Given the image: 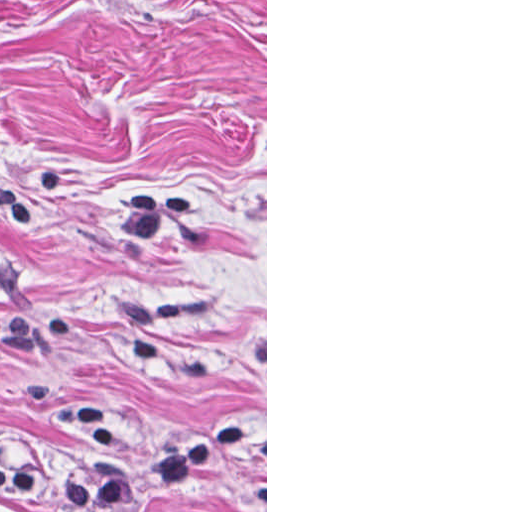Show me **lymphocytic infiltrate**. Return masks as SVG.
Returning <instances> with one entry per match:
<instances>
[{
	"label": "lymphocytic infiltrate",
	"mask_w": 512,
	"mask_h": 512,
	"mask_svg": "<svg viewBox=\"0 0 512 512\" xmlns=\"http://www.w3.org/2000/svg\"><path fill=\"white\" fill-rule=\"evenodd\" d=\"M261 419L219 423L177 449L113 464L97 473H57L0 466V491L79 507H136L200 475L209 465L258 438Z\"/></svg>",
	"instance_id": "1"
}]
</instances>
